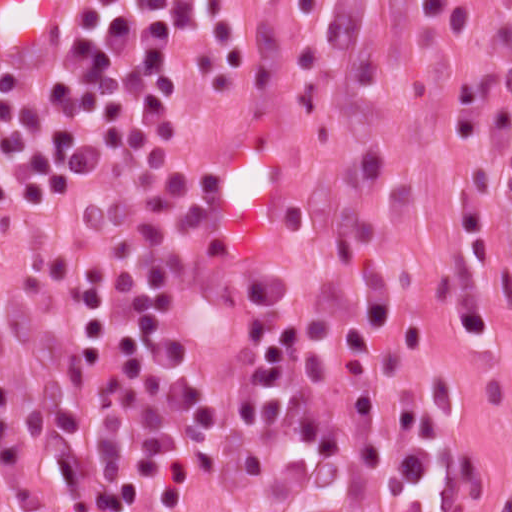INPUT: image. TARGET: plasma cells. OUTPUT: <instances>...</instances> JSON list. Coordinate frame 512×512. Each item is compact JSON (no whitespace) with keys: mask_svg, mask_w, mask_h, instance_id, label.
<instances>
[{"mask_svg":"<svg viewBox=\"0 0 512 512\" xmlns=\"http://www.w3.org/2000/svg\"><path fill=\"white\" fill-rule=\"evenodd\" d=\"M322 0H295L307 20ZM468 23L469 0H417ZM492 30L512 81V0ZM200 33L211 92L225 96L251 62L234 0H79L64 45L29 77L0 80V214L34 217L76 199L107 202L86 245L61 267L42 309L36 371L0 365V512H170L207 439L209 371L182 315L252 318L267 438L258 512H418L432 425L417 395L372 397L387 339L382 259L339 247L315 274L283 265L262 241L207 256L183 143L134 151L170 118L176 42ZM471 153L451 217L450 289L471 338L485 332L493 259L483 217L486 160L512 197V99L495 76L453 96Z\"/></svg>","mask_w":512,"mask_h":512,"instance_id":"9512152a","label":"plasma cells"}]
</instances>
